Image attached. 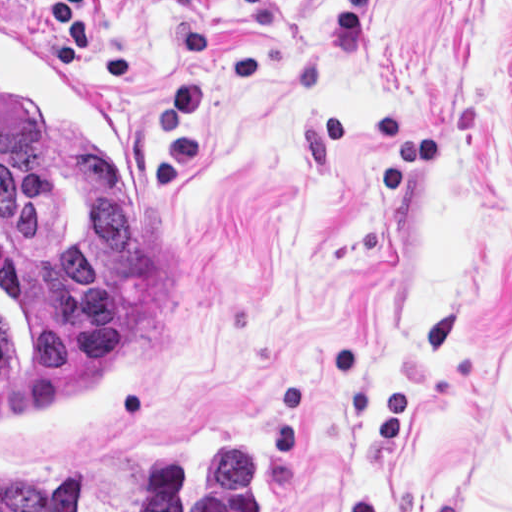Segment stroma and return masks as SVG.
<instances>
[{"instance_id": "obj_1", "label": "stroma", "mask_w": 512, "mask_h": 512, "mask_svg": "<svg viewBox=\"0 0 512 512\" xmlns=\"http://www.w3.org/2000/svg\"><path fill=\"white\" fill-rule=\"evenodd\" d=\"M1 16L61 53L0 0V512L1 474L135 512L173 448H242L255 512H512V0H85L178 313L79 440H1Z\"/></svg>"}]
</instances>
